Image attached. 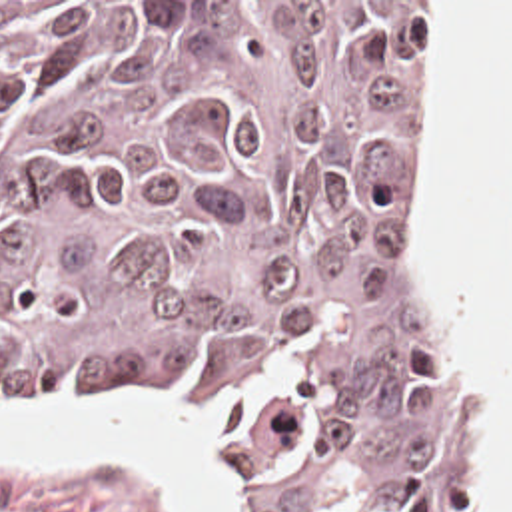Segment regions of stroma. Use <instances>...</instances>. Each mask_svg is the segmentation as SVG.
<instances>
[{
	"mask_svg": "<svg viewBox=\"0 0 512 512\" xmlns=\"http://www.w3.org/2000/svg\"><path fill=\"white\" fill-rule=\"evenodd\" d=\"M0 2H419L421 4V72L411 86L393 132L387 140V208L393 226L397 262L411 311L429 329L439 353L455 373L465 403V497L467 455L473 419V381L453 357L443 327L435 315L413 256V194H415V132L419 124L423 80L427 72V26L433 2H512V0H0ZM44 399H168L209 423L221 443V461L233 479V512H253L243 483L235 425L213 405L196 401L168 383H108L70 391L36 393L20 399H0V413ZM0 512H162L152 495L142 491L116 465H94L80 471H0Z\"/></svg>",
	"mask_w": 512,
	"mask_h": 512,
	"instance_id": "1",
	"label": "stroma"
}]
</instances>
